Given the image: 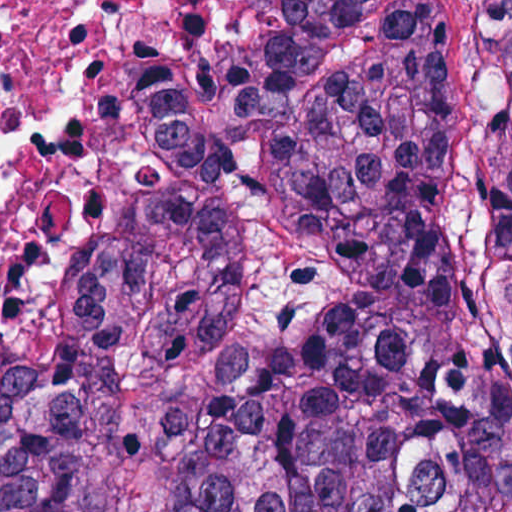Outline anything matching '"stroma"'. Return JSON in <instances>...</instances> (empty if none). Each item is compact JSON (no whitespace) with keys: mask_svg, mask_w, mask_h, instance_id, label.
I'll return each instance as SVG.
<instances>
[{"mask_svg":"<svg viewBox=\"0 0 512 512\" xmlns=\"http://www.w3.org/2000/svg\"><path fill=\"white\" fill-rule=\"evenodd\" d=\"M154 1H512V0H100L86 11L78 27L92 33L105 30ZM147 168V141H146Z\"/></svg>","mask_w":512,"mask_h":512,"instance_id":"obj_1","label":"stroma"}]
</instances>
